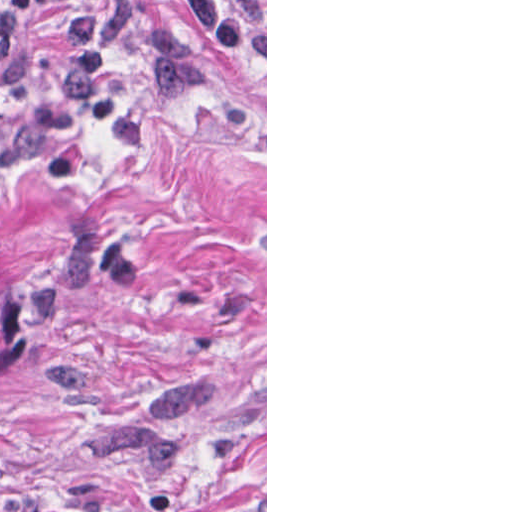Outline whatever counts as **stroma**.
Masks as SVG:
<instances>
[{
	"label": "stroma",
	"mask_w": 512,
	"mask_h": 512,
	"mask_svg": "<svg viewBox=\"0 0 512 512\" xmlns=\"http://www.w3.org/2000/svg\"><path fill=\"white\" fill-rule=\"evenodd\" d=\"M176 28L204 87L132 50L113 87L146 145L88 116L30 164L4 139L52 101L73 0H0V270L27 306L0 377V512H267L266 64ZM235 3L241 0H228Z\"/></svg>",
	"instance_id": "stroma-1"
}]
</instances>
